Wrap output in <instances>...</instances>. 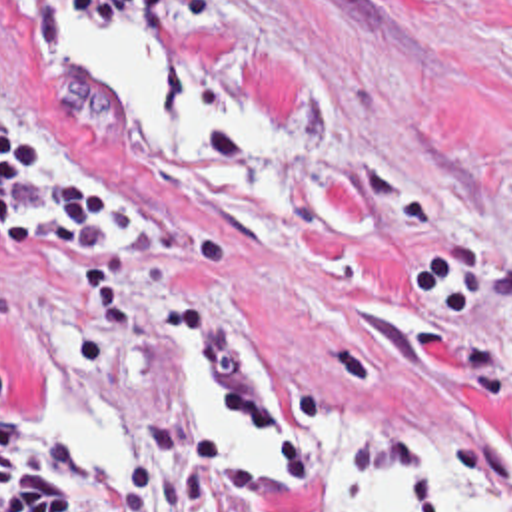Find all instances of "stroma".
Returning a JSON list of instances; mask_svg holds the SVG:
<instances>
[{"mask_svg":"<svg viewBox=\"0 0 512 512\" xmlns=\"http://www.w3.org/2000/svg\"><path fill=\"white\" fill-rule=\"evenodd\" d=\"M60 14L162 44L180 96L266 121L276 149L150 135L70 72ZM0 112L50 167L148 201L150 239L118 247L142 335L180 317L254 409L324 417L374 461L427 445L512 499V0H0ZM88 315L82 261L0 247L20 417L50 427L46 335L82 355ZM256 512L336 511L258 473Z\"/></svg>","mask_w":512,"mask_h":512,"instance_id":"35a3bbf8","label":"stroma"}]
</instances>
